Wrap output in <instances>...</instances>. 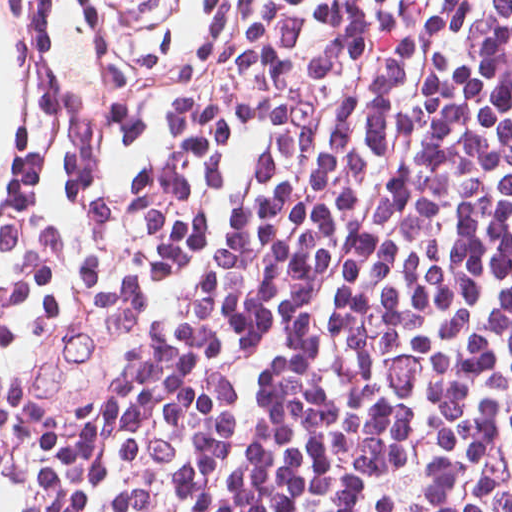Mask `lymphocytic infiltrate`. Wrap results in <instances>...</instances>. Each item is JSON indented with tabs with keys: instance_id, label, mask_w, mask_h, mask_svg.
I'll use <instances>...</instances> for the list:
<instances>
[{
	"instance_id": "lymphocytic-infiltrate-1",
	"label": "lymphocytic infiltrate",
	"mask_w": 512,
	"mask_h": 512,
	"mask_svg": "<svg viewBox=\"0 0 512 512\" xmlns=\"http://www.w3.org/2000/svg\"><path fill=\"white\" fill-rule=\"evenodd\" d=\"M59 512H512V0H233Z\"/></svg>"
}]
</instances>
